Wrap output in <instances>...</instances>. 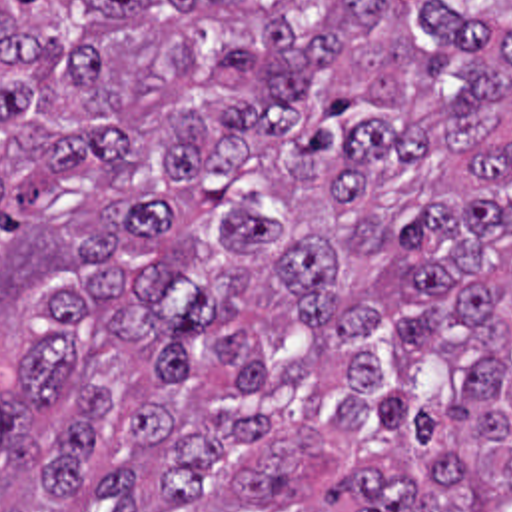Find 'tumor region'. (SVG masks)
<instances>
[{
    "instance_id": "obj_1",
    "label": "tumor region",
    "mask_w": 512,
    "mask_h": 512,
    "mask_svg": "<svg viewBox=\"0 0 512 512\" xmlns=\"http://www.w3.org/2000/svg\"><path fill=\"white\" fill-rule=\"evenodd\" d=\"M0 512H512V0H0Z\"/></svg>"
}]
</instances>
